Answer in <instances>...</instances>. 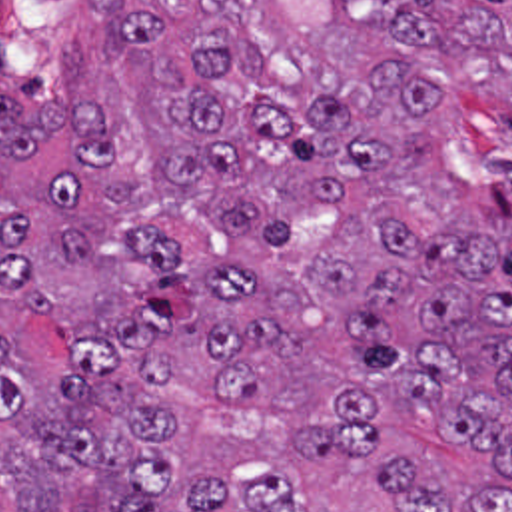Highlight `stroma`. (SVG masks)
Segmentation results:
<instances>
[{
    "instance_id": "35a3bbf8",
    "label": "stroma",
    "mask_w": 512,
    "mask_h": 512,
    "mask_svg": "<svg viewBox=\"0 0 512 512\" xmlns=\"http://www.w3.org/2000/svg\"><path fill=\"white\" fill-rule=\"evenodd\" d=\"M121 0H0V66L31 88H55L117 26ZM93 16L105 36L93 40Z\"/></svg>"
}]
</instances>
